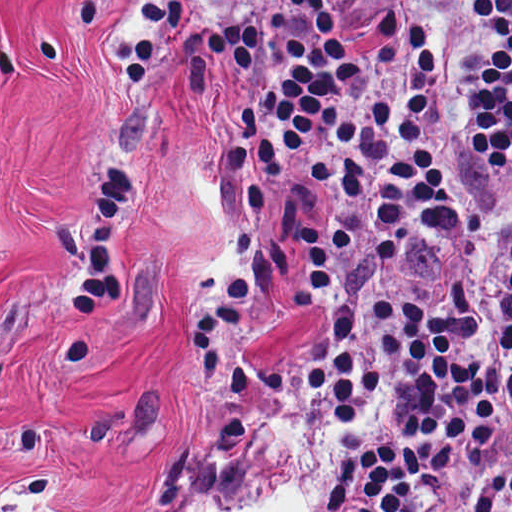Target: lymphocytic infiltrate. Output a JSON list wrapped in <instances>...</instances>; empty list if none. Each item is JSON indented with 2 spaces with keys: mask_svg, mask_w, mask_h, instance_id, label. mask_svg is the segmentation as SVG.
<instances>
[{
  "mask_svg": "<svg viewBox=\"0 0 512 512\" xmlns=\"http://www.w3.org/2000/svg\"><path fill=\"white\" fill-rule=\"evenodd\" d=\"M173 1L196 58L260 70L182 323L201 412L240 320L313 312L294 389L352 437L314 512H453L512 469V0Z\"/></svg>",
  "mask_w": 512,
  "mask_h": 512,
  "instance_id": "f902f5d3",
  "label": "lymphocytic infiltrate"
}]
</instances>
